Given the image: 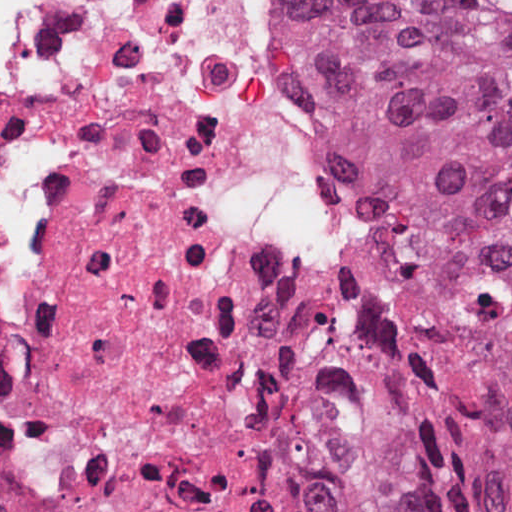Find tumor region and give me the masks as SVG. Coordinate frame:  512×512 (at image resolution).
<instances>
[{
	"instance_id": "tumor-region-1",
	"label": "tumor region",
	"mask_w": 512,
	"mask_h": 512,
	"mask_svg": "<svg viewBox=\"0 0 512 512\" xmlns=\"http://www.w3.org/2000/svg\"><path fill=\"white\" fill-rule=\"evenodd\" d=\"M292 94L388 236L284 361L346 512H512V0H288Z\"/></svg>"
}]
</instances>
